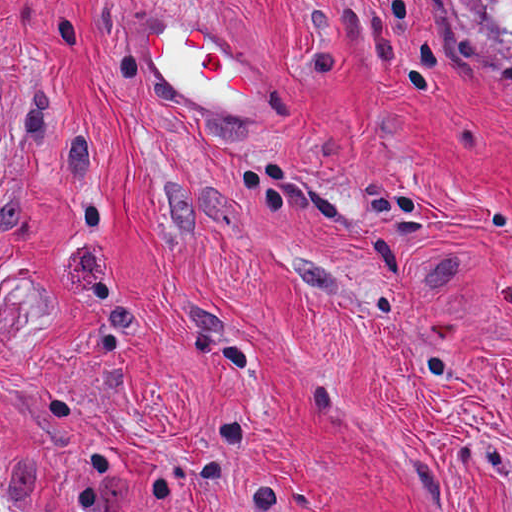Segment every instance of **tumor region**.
<instances>
[{
    "instance_id": "obj_1",
    "label": "tumor region",
    "mask_w": 512,
    "mask_h": 512,
    "mask_svg": "<svg viewBox=\"0 0 512 512\" xmlns=\"http://www.w3.org/2000/svg\"><path fill=\"white\" fill-rule=\"evenodd\" d=\"M444 30L512 59V0H436Z\"/></svg>"
}]
</instances>
